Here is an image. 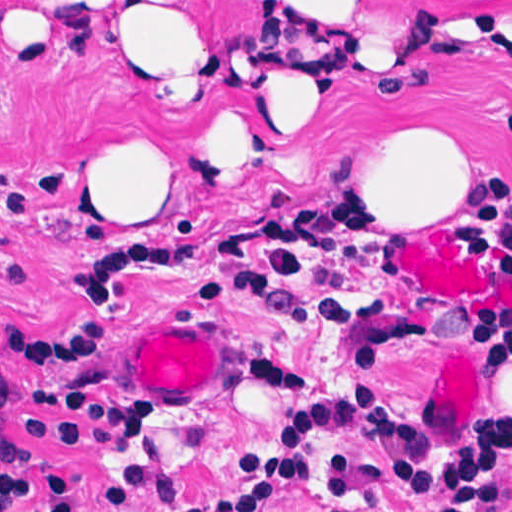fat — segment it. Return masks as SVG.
I'll return each mask as SVG.
<instances>
[{
	"instance_id": "fat-1",
	"label": "fat",
	"mask_w": 512,
	"mask_h": 512,
	"mask_svg": "<svg viewBox=\"0 0 512 512\" xmlns=\"http://www.w3.org/2000/svg\"><path fill=\"white\" fill-rule=\"evenodd\" d=\"M48 12L54 0H36ZM339 0H250L279 38L298 45L247 72L200 120L184 152L201 180L233 183L238 161L305 136L327 108L310 78L338 59L314 46ZM131 65L194 88L198 55L179 21L114 28ZM478 173L472 135L450 108L410 101L357 126V193L418 216L457 205ZM120 210H168L164 175L127 150L114 180Z\"/></svg>"
}]
</instances>
